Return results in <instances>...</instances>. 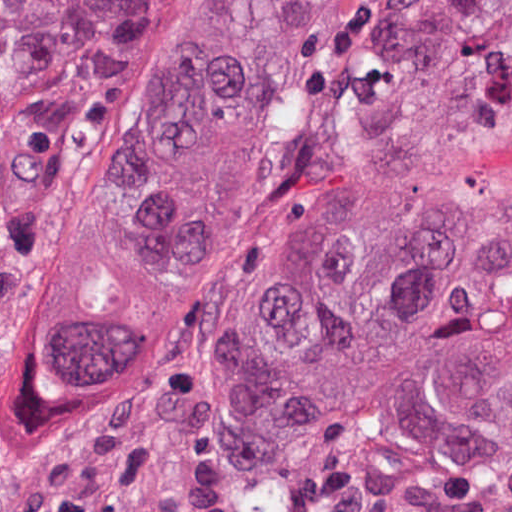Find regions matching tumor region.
<instances>
[{"label": "tumor region", "mask_w": 512, "mask_h": 512, "mask_svg": "<svg viewBox=\"0 0 512 512\" xmlns=\"http://www.w3.org/2000/svg\"><path fill=\"white\" fill-rule=\"evenodd\" d=\"M367 0H206L154 64L79 232L44 395L114 405L205 316ZM140 0H0V229L78 59L137 38ZM512 56V0H387L350 51L279 257L233 344V391L313 395L381 318L444 150Z\"/></svg>", "instance_id": "obj_1"}]
</instances>
